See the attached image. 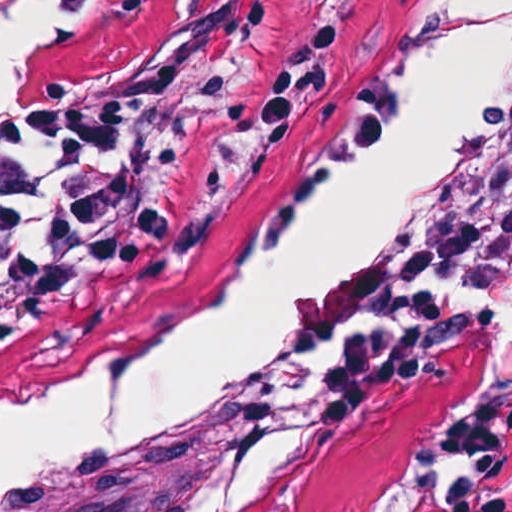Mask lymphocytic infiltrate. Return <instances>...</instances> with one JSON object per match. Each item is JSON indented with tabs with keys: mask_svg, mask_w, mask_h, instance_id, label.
<instances>
[{
	"mask_svg": "<svg viewBox=\"0 0 512 512\" xmlns=\"http://www.w3.org/2000/svg\"><path fill=\"white\" fill-rule=\"evenodd\" d=\"M131 142L113 111L50 100L0 126V353L131 257L146 181L112 165ZM424 498L430 512H512V421L498 397L466 394L433 422Z\"/></svg>",
	"mask_w": 512,
	"mask_h": 512,
	"instance_id": "lymphocytic-infiltrate-1",
	"label": "lymphocytic infiltrate"
}]
</instances>
